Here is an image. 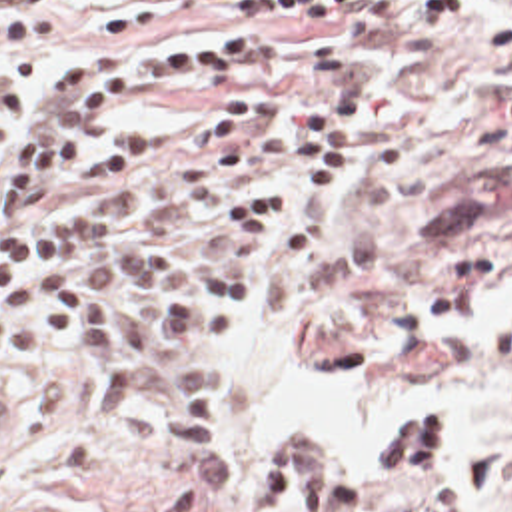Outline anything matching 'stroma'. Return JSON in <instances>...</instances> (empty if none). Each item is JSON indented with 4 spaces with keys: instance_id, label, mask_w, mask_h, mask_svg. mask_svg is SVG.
<instances>
[{
    "instance_id": "stroma-1",
    "label": "stroma",
    "mask_w": 512,
    "mask_h": 512,
    "mask_svg": "<svg viewBox=\"0 0 512 512\" xmlns=\"http://www.w3.org/2000/svg\"><path fill=\"white\" fill-rule=\"evenodd\" d=\"M0 0V16L6 12ZM116 0L58 6L68 22L44 44L0 46V70L50 74L76 52H130L158 38L252 24L174 18L154 30H100ZM493 0L444 22L402 0L362 52L368 88L328 242L288 257V224L306 178L260 248L250 291L294 317L296 349L320 379L360 375L390 405L392 427L426 395L463 411L459 451L436 481L372 485L364 512H512V60L491 54ZM278 58L310 46L312 16L280 18ZM216 104L144 102L106 126L144 144L130 176L72 184L34 210L100 202L168 164ZM0 325V333H2ZM164 337L140 349L166 345ZM222 373L218 447L238 489L206 503L188 459L164 447V399L152 351L146 391L108 419L96 403V351L82 337L12 353L0 343V512H264L268 475L236 447L224 341L200 349ZM430 467H440V449Z\"/></svg>"
}]
</instances>
